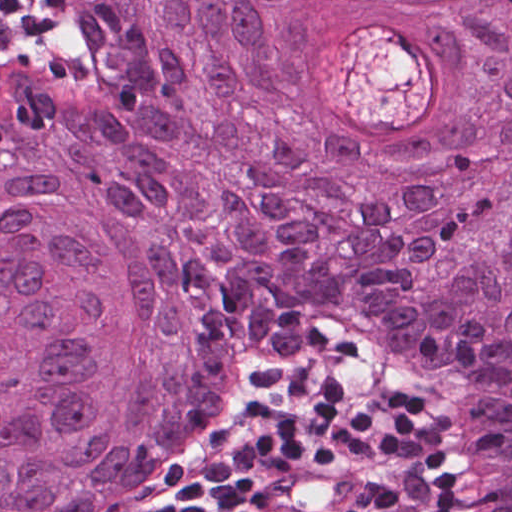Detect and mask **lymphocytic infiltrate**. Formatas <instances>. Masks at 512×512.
I'll return each instance as SVG.
<instances>
[{
    "instance_id": "1",
    "label": "lymphocytic infiltrate",
    "mask_w": 512,
    "mask_h": 512,
    "mask_svg": "<svg viewBox=\"0 0 512 512\" xmlns=\"http://www.w3.org/2000/svg\"><path fill=\"white\" fill-rule=\"evenodd\" d=\"M55 52L44 0H0V59ZM442 430L369 380L298 384L262 404L205 512H434Z\"/></svg>"
}]
</instances>
